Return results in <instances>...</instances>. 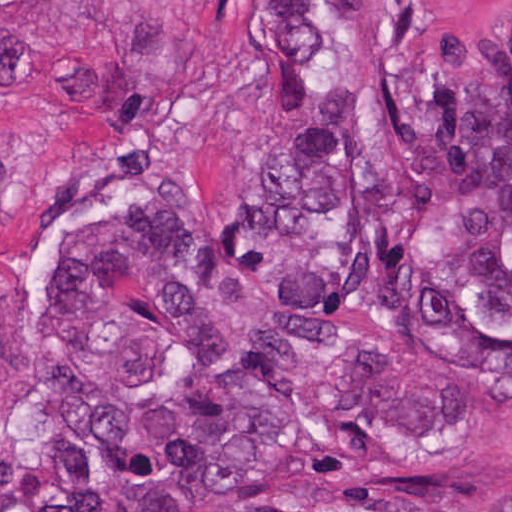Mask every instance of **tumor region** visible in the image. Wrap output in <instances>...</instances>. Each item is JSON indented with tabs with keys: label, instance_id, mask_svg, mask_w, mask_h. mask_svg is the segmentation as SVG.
Masks as SVG:
<instances>
[{
	"label": "tumor region",
	"instance_id": "obj_1",
	"mask_svg": "<svg viewBox=\"0 0 512 512\" xmlns=\"http://www.w3.org/2000/svg\"><path fill=\"white\" fill-rule=\"evenodd\" d=\"M430 2L329 0L276 178L58 268L38 512H304L346 426L512 403V58L438 42Z\"/></svg>",
	"mask_w": 512,
	"mask_h": 512
}]
</instances>
